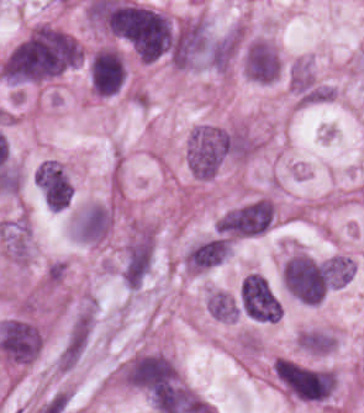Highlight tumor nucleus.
I'll use <instances>...</instances> for the list:
<instances>
[{
  "mask_svg": "<svg viewBox=\"0 0 364 413\" xmlns=\"http://www.w3.org/2000/svg\"><path fill=\"white\" fill-rule=\"evenodd\" d=\"M79 61L73 36L53 27H33L6 54L0 71L14 80L50 77Z\"/></svg>",
  "mask_w": 364,
  "mask_h": 413,
  "instance_id": "1",
  "label": "tumor nucleus"
},
{
  "mask_svg": "<svg viewBox=\"0 0 364 413\" xmlns=\"http://www.w3.org/2000/svg\"><path fill=\"white\" fill-rule=\"evenodd\" d=\"M116 378L156 413L180 382L173 365L155 353L136 355L118 370Z\"/></svg>",
  "mask_w": 364,
  "mask_h": 413,
  "instance_id": "2",
  "label": "tumor nucleus"
},
{
  "mask_svg": "<svg viewBox=\"0 0 364 413\" xmlns=\"http://www.w3.org/2000/svg\"><path fill=\"white\" fill-rule=\"evenodd\" d=\"M118 38L143 60L164 53L170 44L169 21L115 0Z\"/></svg>",
  "mask_w": 364,
  "mask_h": 413,
  "instance_id": "3",
  "label": "tumor nucleus"
},
{
  "mask_svg": "<svg viewBox=\"0 0 364 413\" xmlns=\"http://www.w3.org/2000/svg\"><path fill=\"white\" fill-rule=\"evenodd\" d=\"M273 372L286 393L306 402H321L334 388L332 371L289 359H275Z\"/></svg>",
  "mask_w": 364,
  "mask_h": 413,
  "instance_id": "4",
  "label": "tumor nucleus"
},
{
  "mask_svg": "<svg viewBox=\"0 0 364 413\" xmlns=\"http://www.w3.org/2000/svg\"><path fill=\"white\" fill-rule=\"evenodd\" d=\"M231 137L221 127L200 124L189 138L188 167L193 176H212L226 155Z\"/></svg>",
  "mask_w": 364,
  "mask_h": 413,
  "instance_id": "5",
  "label": "tumor nucleus"
},
{
  "mask_svg": "<svg viewBox=\"0 0 364 413\" xmlns=\"http://www.w3.org/2000/svg\"><path fill=\"white\" fill-rule=\"evenodd\" d=\"M328 268L305 254L285 261L281 273L286 289L305 302H318L324 293Z\"/></svg>",
  "mask_w": 364,
  "mask_h": 413,
  "instance_id": "6",
  "label": "tumor nucleus"
},
{
  "mask_svg": "<svg viewBox=\"0 0 364 413\" xmlns=\"http://www.w3.org/2000/svg\"><path fill=\"white\" fill-rule=\"evenodd\" d=\"M242 306L253 317L262 320H276L280 304L265 277L248 272L242 283Z\"/></svg>",
  "mask_w": 364,
  "mask_h": 413,
  "instance_id": "7",
  "label": "tumor nucleus"
},
{
  "mask_svg": "<svg viewBox=\"0 0 364 413\" xmlns=\"http://www.w3.org/2000/svg\"><path fill=\"white\" fill-rule=\"evenodd\" d=\"M216 232L230 237L263 233V200H249L218 217Z\"/></svg>",
  "mask_w": 364,
  "mask_h": 413,
  "instance_id": "8",
  "label": "tumor nucleus"
},
{
  "mask_svg": "<svg viewBox=\"0 0 364 413\" xmlns=\"http://www.w3.org/2000/svg\"><path fill=\"white\" fill-rule=\"evenodd\" d=\"M124 68L121 55L112 48L95 52L89 62V81L99 95H112L121 85Z\"/></svg>",
  "mask_w": 364,
  "mask_h": 413,
  "instance_id": "9",
  "label": "tumor nucleus"
},
{
  "mask_svg": "<svg viewBox=\"0 0 364 413\" xmlns=\"http://www.w3.org/2000/svg\"><path fill=\"white\" fill-rule=\"evenodd\" d=\"M36 185L47 205L60 209L69 202L73 187L61 167L52 159H44L36 172Z\"/></svg>",
  "mask_w": 364,
  "mask_h": 413,
  "instance_id": "10",
  "label": "tumor nucleus"
},
{
  "mask_svg": "<svg viewBox=\"0 0 364 413\" xmlns=\"http://www.w3.org/2000/svg\"><path fill=\"white\" fill-rule=\"evenodd\" d=\"M228 254V240L222 235H215L190 247L185 266L191 270H206L217 266Z\"/></svg>",
  "mask_w": 364,
  "mask_h": 413,
  "instance_id": "11",
  "label": "tumor nucleus"
},
{
  "mask_svg": "<svg viewBox=\"0 0 364 413\" xmlns=\"http://www.w3.org/2000/svg\"><path fill=\"white\" fill-rule=\"evenodd\" d=\"M206 310L221 319H234L235 300L228 292L211 290L206 295Z\"/></svg>",
  "mask_w": 364,
  "mask_h": 413,
  "instance_id": "12",
  "label": "tumor nucleus"
},
{
  "mask_svg": "<svg viewBox=\"0 0 364 413\" xmlns=\"http://www.w3.org/2000/svg\"><path fill=\"white\" fill-rule=\"evenodd\" d=\"M301 349L327 352L333 346V337L327 330L307 329L299 334Z\"/></svg>",
  "mask_w": 364,
  "mask_h": 413,
  "instance_id": "13",
  "label": "tumor nucleus"
}]
</instances>
